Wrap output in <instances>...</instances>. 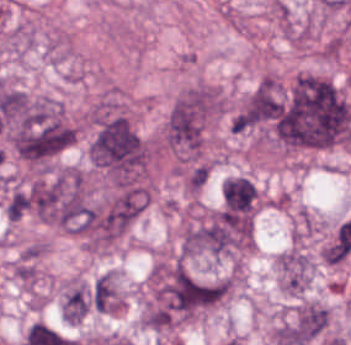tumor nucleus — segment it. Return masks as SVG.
<instances>
[{"instance_id":"tumor-nucleus-2","label":"tumor nucleus","mask_w":351,"mask_h":345,"mask_svg":"<svg viewBox=\"0 0 351 345\" xmlns=\"http://www.w3.org/2000/svg\"><path fill=\"white\" fill-rule=\"evenodd\" d=\"M281 96L274 77H260L229 120L231 130H244L269 122L280 110Z\"/></svg>"},{"instance_id":"tumor-nucleus-1","label":"tumor nucleus","mask_w":351,"mask_h":345,"mask_svg":"<svg viewBox=\"0 0 351 345\" xmlns=\"http://www.w3.org/2000/svg\"><path fill=\"white\" fill-rule=\"evenodd\" d=\"M269 136L291 148L328 147L351 138V108L328 78L301 73L282 89L269 123Z\"/></svg>"},{"instance_id":"tumor-nucleus-3","label":"tumor nucleus","mask_w":351,"mask_h":345,"mask_svg":"<svg viewBox=\"0 0 351 345\" xmlns=\"http://www.w3.org/2000/svg\"><path fill=\"white\" fill-rule=\"evenodd\" d=\"M223 211L253 214L256 186L243 176H229L221 187Z\"/></svg>"},{"instance_id":"tumor-nucleus-6","label":"tumor nucleus","mask_w":351,"mask_h":345,"mask_svg":"<svg viewBox=\"0 0 351 345\" xmlns=\"http://www.w3.org/2000/svg\"><path fill=\"white\" fill-rule=\"evenodd\" d=\"M90 307L89 290L83 283H75L67 289L61 310L68 323H78Z\"/></svg>"},{"instance_id":"tumor-nucleus-5","label":"tumor nucleus","mask_w":351,"mask_h":345,"mask_svg":"<svg viewBox=\"0 0 351 345\" xmlns=\"http://www.w3.org/2000/svg\"><path fill=\"white\" fill-rule=\"evenodd\" d=\"M328 316L327 308L313 301H306L295 311L294 319L304 345L324 331Z\"/></svg>"},{"instance_id":"tumor-nucleus-7","label":"tumor nucleus","mask_w":351,"mask_h":345,"mask_svg":"<svg viewBox=\"0 0 351 345\" xmlns=\"http://www.w3.org/2000/svg\"><path fill=\"white\" fill-rule=\"evenodd\" d=\"M30 206L27 190L13 189L4 203L5 213L9 220H16Z\"/></svg>"},{"instance_id":"tumor-nucleus-4","label":"tumor nucleus","mask_w":351,"mask_h":345,"mask_svg":"<svg viewBox=\"0 0 351 345\" xmlns=\"http://www.w3.org/2000/svg\"><path fill=\"white\" fill-rule=\"evenodd\" d=\"M281 286L285 291L306 289L309 279V262L304 253L289 250L276 260Z\"/></svg>"}]
</instances>
